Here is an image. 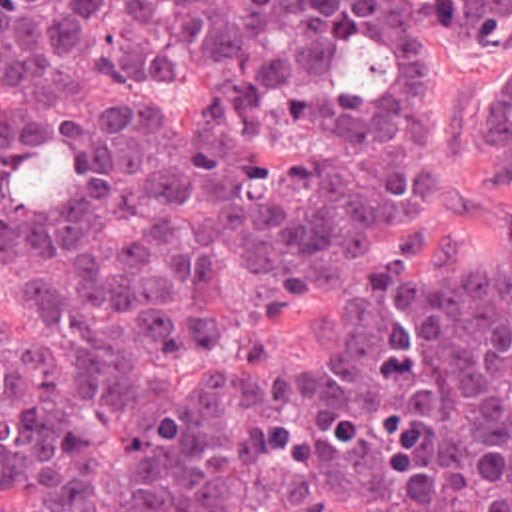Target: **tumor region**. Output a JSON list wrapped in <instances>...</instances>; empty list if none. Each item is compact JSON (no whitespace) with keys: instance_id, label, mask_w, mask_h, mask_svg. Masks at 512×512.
<instances>
[{"instance_id":"tumor-region-1","label":"tumor region","mask_w":512,"mask_h":512,"mask_svg":"<svg viewBox=\"0 0 512 512\" xmlns=\"http://www.w3.org/2000/svg\"><path fill=\"white\" fill-rule=\"evenodd\" d=\"M512 46V0H0V463L29 512H512L500 261L384 221L424 201L430 46ZM480 143L512 171V52ZM314 285L340 357L260 319Z\"/></svg>"}]
</instances>
